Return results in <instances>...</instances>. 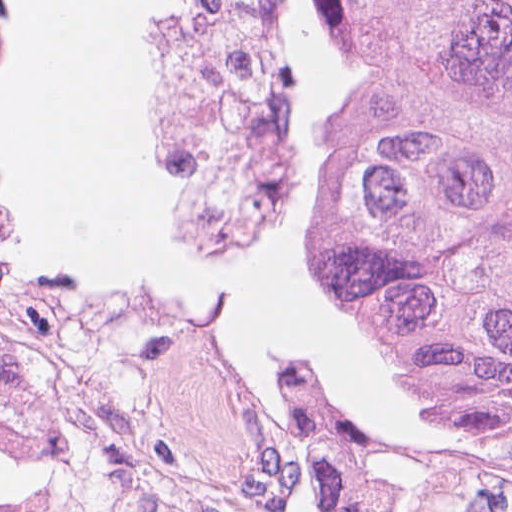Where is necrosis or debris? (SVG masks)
I'll use <instances>...</instances> for the list:
<instances>
[{"label": "necrosis or debris", "instance_id": "necrosis-or-debris-1", "mask_svg": "<svg viewBox=\"0 0 512 512\" xmlns=\"http://www.w3.org/2000/svg\"><path fill=\"white\" fill-rule=\"evenodd\" d=\"M280 0H156L145 48L152 193L188 241L266 265L288 246L299 124ZM0 512H310L184 429L0 411Z\"/></svg>", "mask_w": 512, "mask_h": 512}]
</instances>
